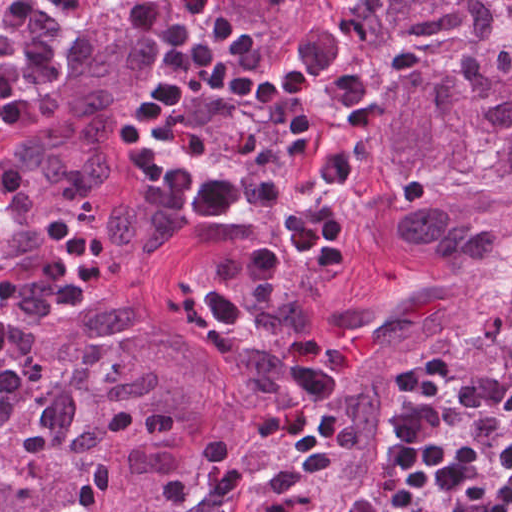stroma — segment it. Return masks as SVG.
I'll return each instance as SVG.
<instances>
[{"label":"stroma","mask_w":512,"mask_h":512,"mask_svg":"<svg viewBox=\"0 0 512 512\" xmlns=\"http://www.w3.org/2000/svg\"><path fill=\"white\" fill-rule=\"evenodd\" d=\"M325 11L393 70L404 37L382 23L371 0H326Z\"/></svg>","instance_id":"obj_1"}]
</instances>
